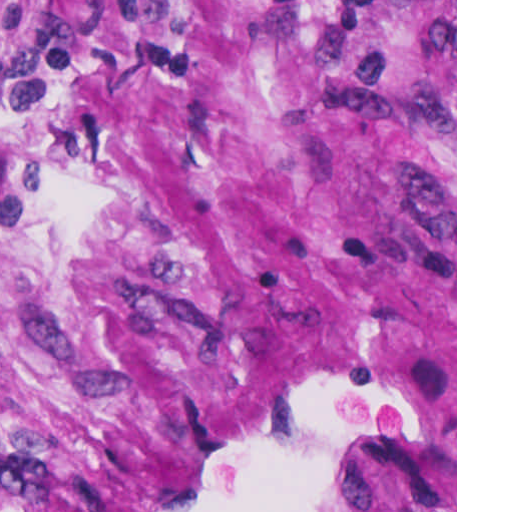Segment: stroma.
Here are the masks:
<instances>
[{"instance_id": "1", "label": "stroma", "mask_w": 512, "mask_h": 512, "mask_svg": "<svg viewBox=\"0 0 512 512\" xmlns=\"http://www.w3.org/2000/svg\"><path fill=\"white\" fill-rule=\"evenodd\" d=\"M0 512H457V0H0Z\"/></svg>"}]
</instances>
